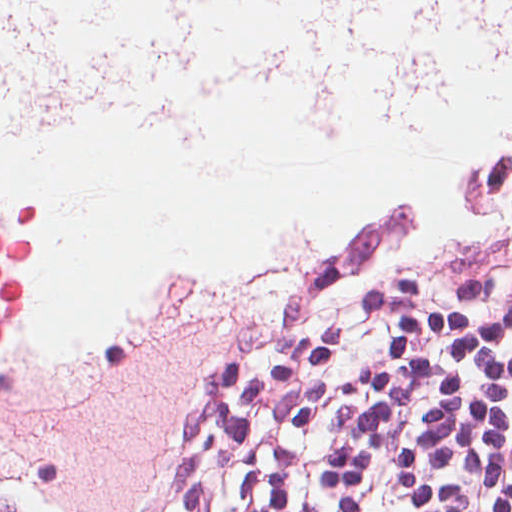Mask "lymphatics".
Wrapping results in <instances>:
<instances>
[{
    "label": "lymphatics",
    "instance_id": "1",
    "mask_svg": "<svg viewBox=\"0 0 512 512\" xmlns=\"http://www.w3.org/2000/svg\"><path fill=\"white\" fill-rule=\"evenodd\" d=\"M512 58V0H201L169 151L212 163L230 109L280 98L319 133H425L445 93ZM232 242L135 310L92 512L127 479L160 403L306 230ZM271 240H283V250Z\"/></svg>",
    "mask_w": 512,
    "mask_h": 512
}]
</instances>
